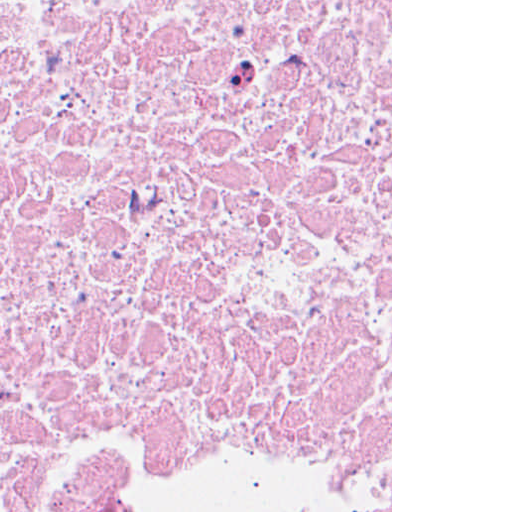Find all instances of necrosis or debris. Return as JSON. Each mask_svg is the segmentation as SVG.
Segmentation results:
<instances>
[{"label":"necrosis or debris","instance_id":"1","mask_svg":"<svg viewBox=\"0 0 512 512\" xmlns=\"http://www.w3.org/2000/svg\"><path fill=\"white\" fill-rule=\"evenodd\" d=\"M391 512V0H0V512Z\"/></svg>","mask_w":512,"mask_h":512}]
</instances>
